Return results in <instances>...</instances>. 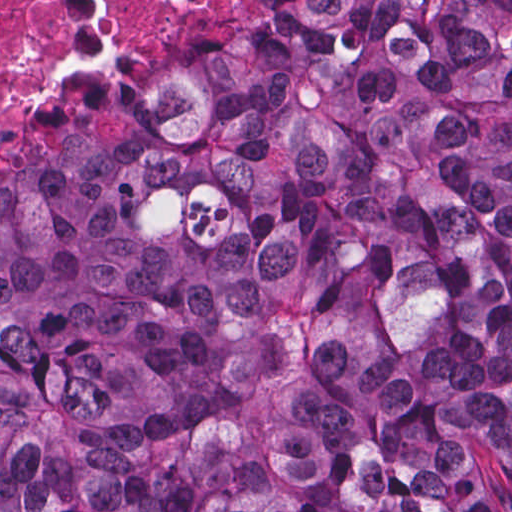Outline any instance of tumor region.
Returning <instances> with one entry per match:
<instances>
[{"label":"tumor region","mask_w":512,"mask_h":512,"mask_svg":"<svg viewBox=\"0 0 512 512\" xmlns=\"http://www.w3.org/2000/svg\"><path fill=\"white\" fill-rule=\"evenodd\" d=\"M0 512H512V0H270L0 184Z\"/></svg>","instance_id":"e687c5a6"}]
</instances>
